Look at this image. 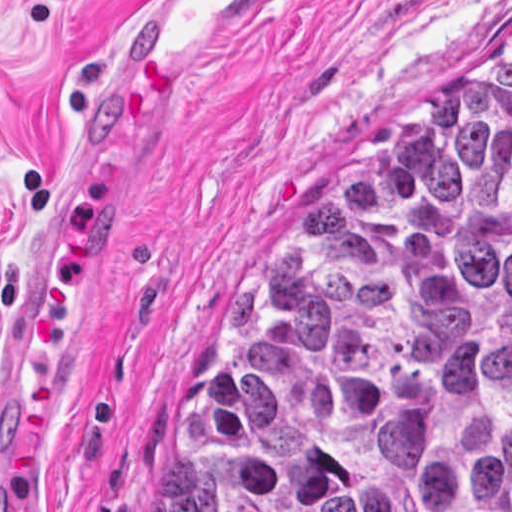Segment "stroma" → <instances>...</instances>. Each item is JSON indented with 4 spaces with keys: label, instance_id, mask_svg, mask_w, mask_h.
Returning <instances> with one entry per match:
<instances>
[{
    "label": "stroma",
    "instance_id": "1",
    "mask_svg": "<svg viewBox=\"0 0 512 512\" xmlns=\"http://www.w3.org/2000/svg\"><path fill=\"white\" fill-rule=\"evenodd\" d=\"M134 0H0V512H132L346 136L512 47V0H308L165 133L24 169Z\"/></svg>",
    "mask_w": 512,
    "mask_h": 512
}]
</instances>
